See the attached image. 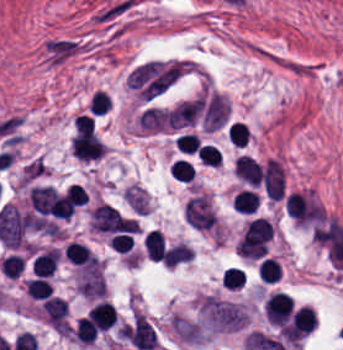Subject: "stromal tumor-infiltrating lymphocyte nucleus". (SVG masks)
<instances>
[{"mask_svg": "<svg viewBox=\"0 0 343 350\" xmlns=\"http://www.w3.org/2000/svg\"><path fill=\"white\" fill-rule=\"evenodd\" d=\"M22 270V256L10 254L1 259L0 272L9 278H17Z\"/></svg>", "mask_w": 343, "mask_h": 350, "instance_id": "obj_8", "label": "stromal tumor-infiltrating lymphocyte nucleus"}, {"mask_svg": "<svg viewBox=\"0 0 343 350\" xmlns=\"http://www.w3.org/2000/svg\"><path fill=\"white\" fill-rule=\"evenodd\" d=\"M279 262L271 257H264L258 264V278L262 282L274 283L279 276Z\"/></svg>", "mask_w": 343, "mask_h": 350, "instance_id": "obj_5", "label": "stromal tumor-infiltrating lymphocyte nucleus"}, {"mask_svg": "<svg viewBox=\"0 0 343 350\" xmlns=\"http://www.w3.org/2000/svg\"><path fill=\"white\" fill-rule=\"evenodd\" d=\"M87 316L98 331H105L115 324L116 312L110 303L99 302L88 310Z\"/></svg>", "mask_w": 343, "mask_h": 350, "instance_id": "obj_1", "label": "stromal tumor-infiltrating lymphocyte nucleus"}, {"mask_svg": "<svg viewBox=\"0 0 343 350\" xmlns=\"http://www.w3.org/2000/svg\"><path fill=\"white\" fill-rule=\"evenodd\" d=\"M223 281L227 289H241L244 285L243 271L241 267H227L222 273Z\"/></svg>", "mask_w": 343, "mask_h": 350, "instance_id": "obj_12", "label": "stromal tumor-infiltrating lymphocyte nucleus"}, {"mask_svg": "<svg viewBox=\"0 0 343 350\" xmlns=\"http://www.w3.org/2000/svg\"><path fill=\"white\" fill-rule=\"evenodd\" d=\"M64 257L74 264H96V256L84 244L70 241L63 249Z\"/></svg>", "mask_w": 343, "mask_h": 350, "instance_id": "obj_2", "label": "stromal tumor-infiltrating lymphocyte nucleus"}, {"mask_svg": "<svg viewBox=\"0 0 343 350\" xmlns=\"http://www.w3.org/2000/svg\"><path fill=\"white\" fill-rule=\"evenodd\" d=\"M169 174L178 181L191 182L192 165L184 159H177L170 167Z\"/></svg>", "mask_w": 343, "mask_h": 350, "instance_id": "obj_11", "label": "stromal tumor-infiltrating lymphocyte nucleus"}, {"mask_svg": "<svg viewBox=\"0 0 343 350\" xmlns=\"http://www.w3.org/2000/svg\"><path fill=\"white\" fill-rule=\"evenodd\" d=\"M25 288L29 295L36 299H46L51 297L52 288L47 278L35 277L26 281Z\"/></svg>", "mask_w": 343, "mask_h": 350, "instance_id": "obj_6", "label": "stromal tumor-infiltrating lymphocyte nucleus"}, {"mask_svg": "<svg viewBox=\"0 0 343 350\" xmlns=\"http://www.w3.org/2000/svg\"><path fill=\"white\" fill-rule=\"evenodd\" d=\"M259 201L253 191L241 189L231 200L232 210L253 214Z\"/></svg>", "mask_w": 343, "mask_h": 350, "instance_id": "obj_4", "label": "stromal tumor-infiltrating lymphocyte nucleus"}, {"mask_svg": "<svg viewBox=\"0 0 343 350\" xmlns=\"http://www.w3.org/2000/svg\"><path fill=\"white\" fill-rule=\"evenodd\" d=\"M199 161L206 166H217L221 162V155L210 144H203L198 150Z\"/></svg>", "mask_w": 343, "mask_h": 350, "instance_id": "obj_13", "label": "stromal tumor-infiltrating lymphocyte nucleus"}, {"mask_svg": "<svg viewBox=\"0 0 343 350\" xmlns=\"http://www.w3.org/2000/svg\"><path fill=\"white\" fill-rule=\"evenodd\" d=\"M111 101L104 91L95 90L89 100L88 111L93 115H102L106 113Z\"/></svg>", "mask_w": 343, "mask_h": 350, "instance_id": "obj_10", "label": "stromal tumor-infiltrating lymphocyte nucleus"}, {"mask_svg": "<svg viewBox=\"0 0 343 350\" xmlns=\"http://www.w3.org/2000/svg\"><path fill=\"white\" fill-rule=\"evenodd\" d=\"M175 143L181 153L192 155L199 148L201 140L196 133H183Z\"/></svg>", "mask_w": 343, "mask_h": 350, "instance_id": "obj_9", "label": "stromal tumor-infiltrating lymphocyte nucleus"}, {"mask_svg": "<svg viewBox=\"0 0 343 350\" xmlns=\"http://www.w3.org/2000/svg\"><path fill=\"white\" fill-rule=\"evenodd\" d=\"M143 249L153 261H162L164 254V238L159 230H151L143 236Z\"/></svg>", "mask_w": 343, "mask_h": 350, "instance_id": "obj_3", "label": "stromal tumor-infiltrating lymphocyte nucleus"}, {"mask_svg": "<svg viewBox=\"0 0 343 350\" xmlns=\"http://www.w3.org/2000/svg\"><path fill=\"white\" fill-rule=\"evenodd\" d=\"M227 136L232 145L243 147L249 137V133L245 123L235 120L227 127Z\"/></svg>", "mask_w": 343, "mask_h": 350, "instance_id": "obj_7", "label": "stromal tumor-infiltrating lymphocyte nucleus"}]
</instances>
